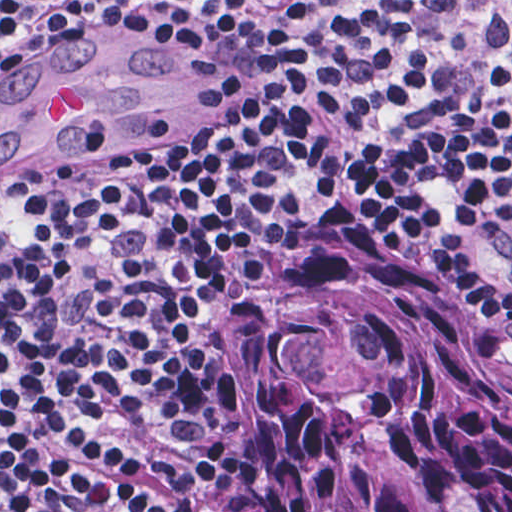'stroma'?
<instances>
[{
	"mask_svg": "<svg viewBox=\"0 0 512 512\" xmlns=\"http://www.w3.org/2000/svg\"><path fill=\"white\" fill-rule=\"evenodd\" d=\"M0 1H120L76 23L25 45L12 70L60 39L97 26L136 22L137 18L168 23H147L177 32L174 65L144 142L163 140L187 127L205 107L209 65L196 41L200 9L210 1H512V0H0ZM141 144V143H139Z\"/></svg>",
	"mask_w": 512,
	"mask_h": 512,
	"instance_id": "35a3bbf8",
	"label": "stroma"
}]
</instances>
